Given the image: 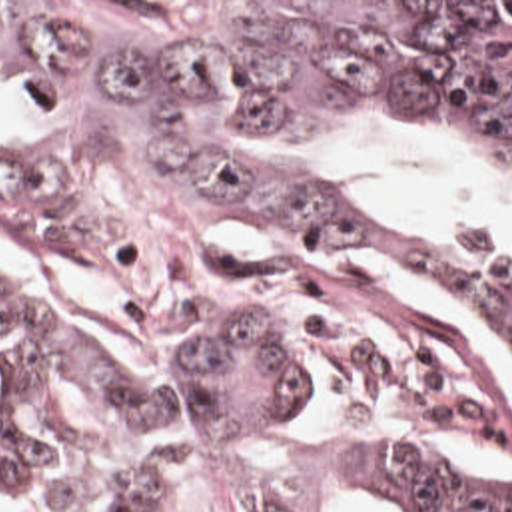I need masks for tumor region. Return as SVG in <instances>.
Listing matches in <instances>:
<instances>
[{
    "label": "tumor region",
    "mask_w": 512,
    "mask_h": 512,
    "mask_svg": "<svg viewBox=\"0 0 512 512\" xmlns=\"http://www.w3.org/2000/svg\"><path fill=\"white\" fill-rule=\"evenodd\" d=\"M0 78L43 126H0V230L95 289L223 291L179 353L127 361L57 333L0 411V485L59 512L175 509L207 487L257 512L373 495L430 512H512V479L397 439L305 445L295 357L498 433L480 379L411 347L255 315L259 281L221 226L359 232L444 254L484 285L512 359V254L339 186L353 124L419 128L512 176V2H0ZM31 319L0 279V335Z\"/></svg>",
    "instance_id": "1"
}]
</instances>
